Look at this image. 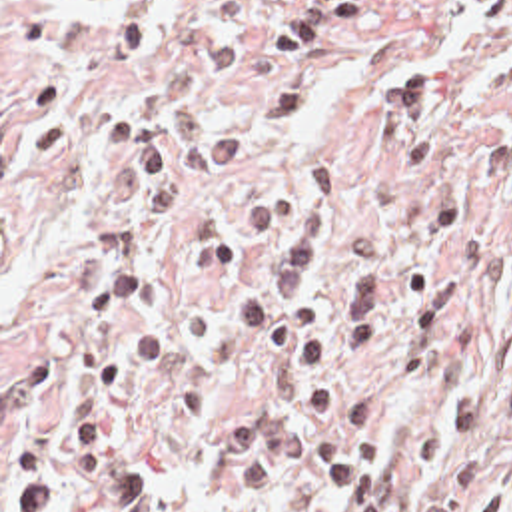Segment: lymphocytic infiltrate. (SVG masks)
<instances>
[{"label": "lymphocytic infiltrate", "mask_w": 512, "mask_h": 512, "mask_svg": "<svg viewBox=\"0 0 512 512\" xmlns=\"http://www.w3.org/2000/svg\"><path fill=\"white\" fill-rule=\"evenodd\" d=\"M512 19V0H485L483 35ZM333 189L329 155L317 153L284 183L238 207L244 235L282 237L262 277L240 291L236 329L258 355H303V420L329 430L305 434L319 492L343 512H399L383 458L377 410L351 365L355 355L395 380H419L453 353L461 329V285L439 269L417 271L391 299L383 243L359 235L333 277L325 305L313 301L317 233ZM481 462L467 458L427 512H477ZM512 512V510H511Z\"/></svg>", "instance_id": "1"}]
</instances>
